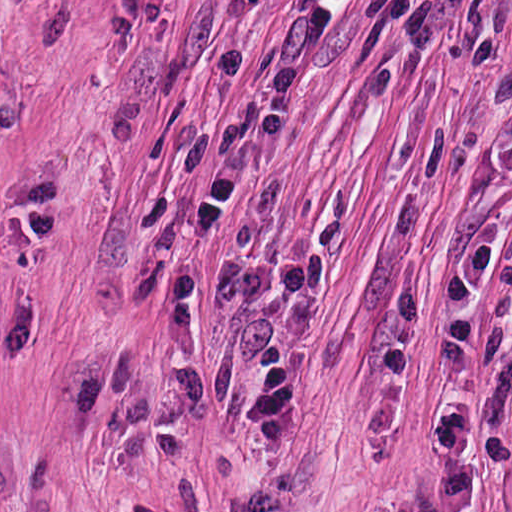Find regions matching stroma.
<instances>
[{"label": "stroma", "mask_w": 512, "mask_h": 512, "mask_svg": "<svg viewBox=\"0 0 512 512\" xmlns=\"http://www.w3.org/2000/svg\"><path fill=\"white\" fill-rule=\"evenodd\" d=\"M370 0L205 512H414L442 481L443 269L512 238V0H454L439 50ZM463 512H512V309L483 294Z\"/></svg>", "instance_id": "obj_1"}]
</instances>
